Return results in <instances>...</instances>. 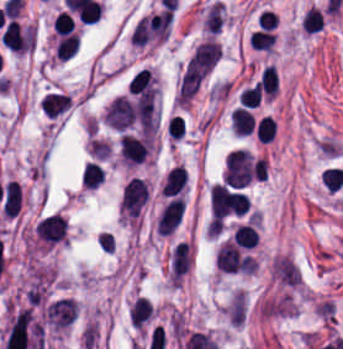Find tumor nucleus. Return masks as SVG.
Returning <instances> with one entry per match:
<instances>
[{
    "label": "tumor nucleus",
    "instance_id": "tumor-nucleus-1",
    "mask_svg": "<svg viewBox=\"0 0 343 349\" xmlns=\"http://www.w3.org/2000/svg\"><path fill=\"white\" fill-rule=\"evenodd\" d=\"M327 167H328V170L330 172L335 189L337 191L343 186V182H342L341 178L339 177L338 173L336 172L333 165H327Z\"/></svg>",
    "mask_w": 343,
    "mask_h": 349
},
{
    "label": "tumor nucleus",
    "instance_id": "tumor-nucleus-2",
    "mask_svg": "<svg viewBox=\"0 0 343 349\" xmlns=\"http://www.w3.org/2000/svg\"><path fill=\"white\" fill-rule=\"evenodd\" d=\"M153 318H154V316L151 318V320L146 324V326L143 329H147L148 328V326L151 324Z\"/></svg>",
    "mask_w": 343,
    "mask_h": 349
}]
</instances>
